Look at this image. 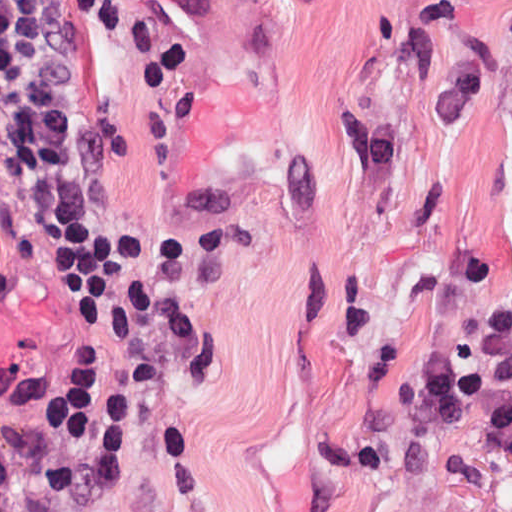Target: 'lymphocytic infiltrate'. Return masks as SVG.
I'll return each mask as SVG.
<instances>
[{"label": "lymphocytic infiltrate", "instance_id": "lymphocytic-infiltrate-1", "mask_svg": "<svg viewBox=\"0 0 512 512\" xmlns=\"http://www.w3.org/2000/svg\"><path fill=\"white\" fill-rule=\"evenodd\" d=\"M0 135L38 162L41 208L83 286L137 268L150 234L104 164L70 0H0ZM71 351L62 353L42 395V436L102 471H128L145 442L144 406L111 364ZM0 512H63L23 458L1 360Z\"/></svg>", "mask_w": 512, "mask_h": 512}]
</instances>
